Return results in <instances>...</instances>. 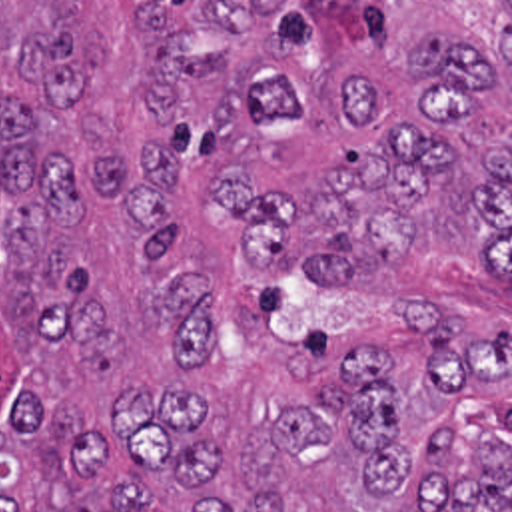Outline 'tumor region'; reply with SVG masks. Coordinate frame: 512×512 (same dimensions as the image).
Here are the masks:
<instances>
[{"label": "tumor region", "instance_id": "1", "mask_svg": "<svg viewBox=\"0 0 512 512\" xmlns=\"http://www.w3.org/2000/svg\"><path fill=\"white\" fill-rule=\"evenodd\" d=\"M512 2H0V512H512V329L279 327L438 258L512 285Z\"/></svg>", "mask_w": 512, "mask_h": 512}]
</instances>
